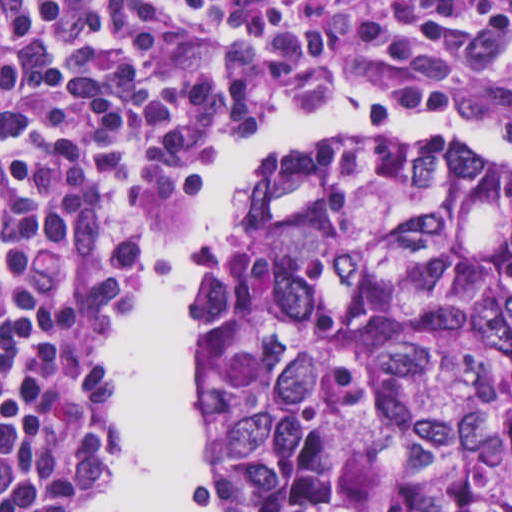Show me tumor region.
Listing matches in <instances>:
<instances>
[{
	"label": "tumor region",
	"mask_w": 512,
	"mask_h": 512,
	"mask_svg": "<svg viewBox=\"0 0 512 512\" xmlns=\"http://www.w3.org/2000/svg\"><path fill=\"white\" fill-rule=\"evenodd\" d=\"M222 512H512V163L264 160L184 299Z\"/></svg>",
	"instance_id": "tumor-region-1"
}]
</instances>
